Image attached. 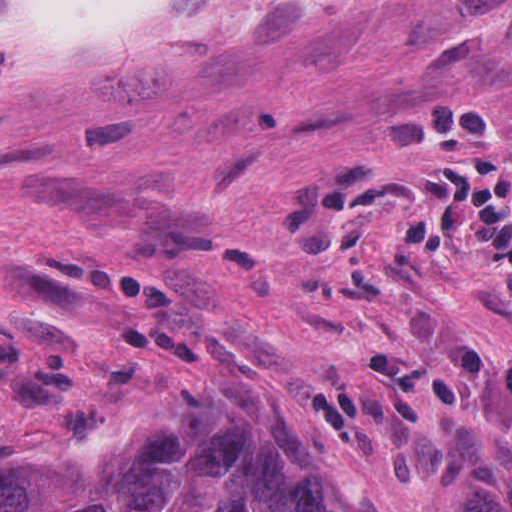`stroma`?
<instances>
[{"label": "stroma", "instance_id": "1", "mask_svg": "<svg viewBox=\"0 0 512 512\" xmlns=\"http://www.w3.org/2000/svg\"><path fill=\"white\" fill-rule=\"evenodd\" d=\"M270 386L367 512H512V0H304L8 64L9 449L87 456L180 385Z\"/></svg>", "mask_w": 512, "mask_h": 512}]
</instances>
